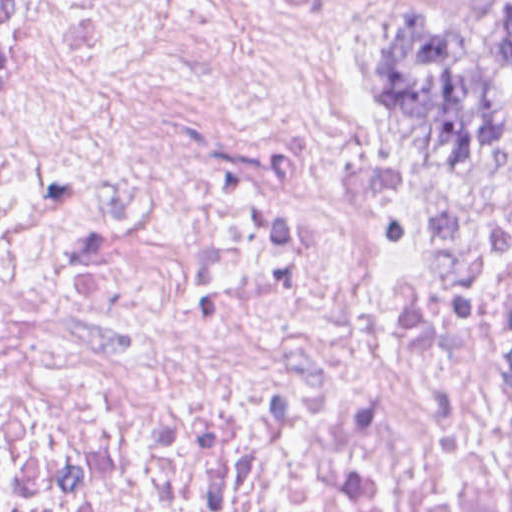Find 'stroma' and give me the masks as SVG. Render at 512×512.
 Here are the masks:
<instances>
[{"label":"stroma","mask_w":512,"mask_h":512,"mask_svg":"<svg viewBox=\"0 0 512 512\" xmlns=\"http://www.w3.org/2000/svg\"><path fill=\"white\" fill-rule=\"evenodd\" d=\"M293 17L325 53L343 139L393 191L488 216H512V171L464 178L442 165L387 99L378 78V19L487 0H239ZM462 168V167H457Z\"/></svg>","instance_id":"35a3bbf8"}]
</instances>
